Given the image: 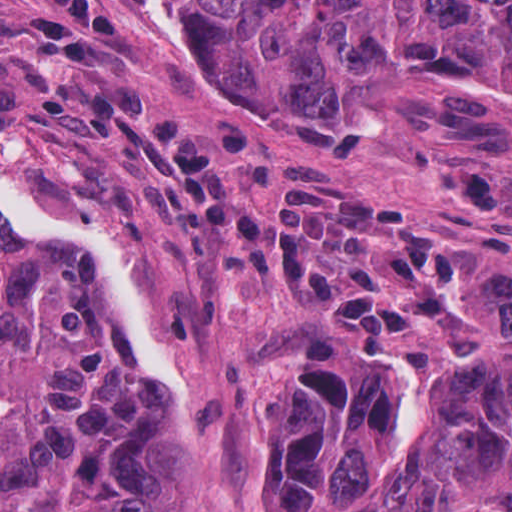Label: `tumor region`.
<instances>
[{
  "label": "tumor region",
  "instance_id": "e687c5a6",
  "mask_svg": "<svg viewBox=\"0 0 512 512\" xmlns=\"http://www.w3.org/2000/svg\"><path fill=\"white\" fill-rule=\"evenodd\" d=\"M162 1L234 67L345 105L450 88L512 126V0ZM501 300L484 356L435 370L407 451V369L328 333L276 336L261 512H372L384 494L383 512L512 507V284ZM114 314L83 252L0 216V512H205L180 396L155 397Z\"/></svg>",
  "mask_w": 512,
  "mask_h": 512
}]
</instances>
